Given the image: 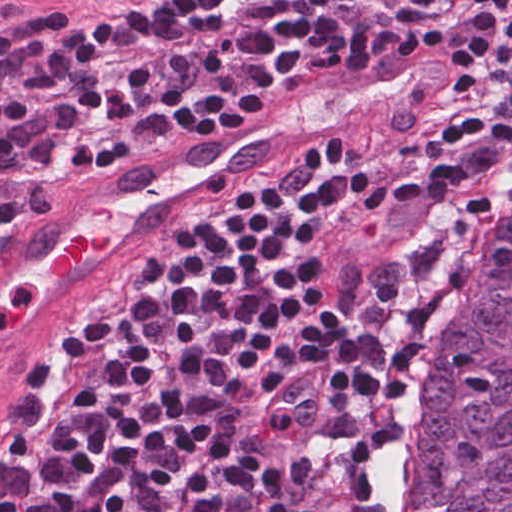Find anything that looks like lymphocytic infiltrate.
I'll return each instance as SVG.
<instances>
[{
    "instance_id": "f902f5d3",
    "label": "lymphocytic infiltrate",
    "mask_w": 512,
    "mask_h": 512,
    "mask_svg": "<svg viewBox=\"0 0 512 512\" xmlns=\"http://www.w3.org/2000/svg\"><path fill=\"white\" fill-rule=\"evenodd\" d=\"M475 48L496 121L442 165L345 170L346 134L181 216L119 289L40 339L0 431L31 512H379L363 462L282 425L356 411L403 438L512 239V0H168L0 20V257L155 147L254 120L423 20ZM0 512H17L0 471Z\"/></svg>"
}]
</instances>
